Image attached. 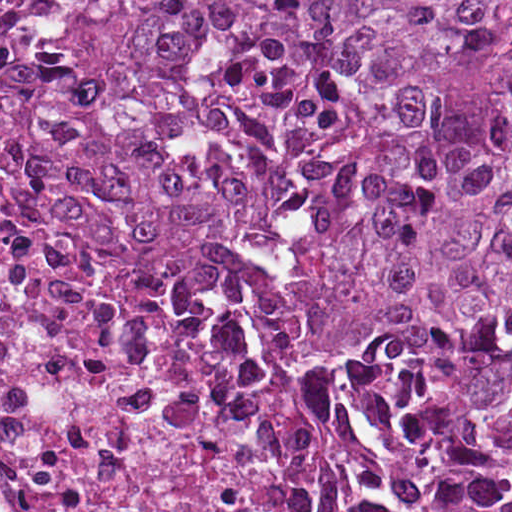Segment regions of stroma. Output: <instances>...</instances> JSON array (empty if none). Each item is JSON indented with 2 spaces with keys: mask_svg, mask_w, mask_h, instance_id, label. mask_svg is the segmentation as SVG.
<instances>
[{
  "mask_svg": "<svg viewBox=\"0 0 512 512\" xmlns=\"http://www.w3.org/2000/svg\"><path fill=\"white\" fill-rule=\"evenodd\" d=\"M81 1L55 60L34 137V181L69 244L96 253L135 275L199 332L223 341L246 364L261 400L308 424L364 472L379 493L433 512L425 496L395 489L381 469L369 403L350 375L325 357L298 355L238 283L225 276L162 279L129 268L96 248L73 219L68 162V89L100 30L111 1H508L512 0H0Z\"/></svg>",
  "mask_w": 512,
  "mask_h": 512,
  "instance_id": "1",
  "label": "stroma"
}]
</instances>
